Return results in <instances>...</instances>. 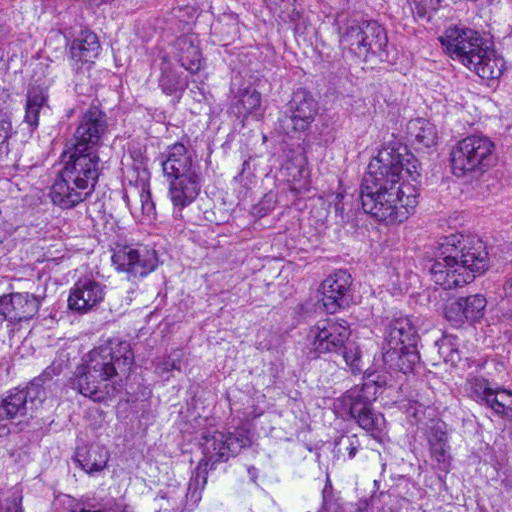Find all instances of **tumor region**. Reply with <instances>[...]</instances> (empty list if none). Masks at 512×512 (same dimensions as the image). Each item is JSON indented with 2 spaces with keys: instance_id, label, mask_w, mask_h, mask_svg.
I'll use <instances>...</instances> for the list:
<instances>
[{
  "instance_id": "e687c5a6",
  "label": "tumor region",
  "mask_w": 512,
  "mask_h": 512,
  "mask_svg": "<svg viewBox=\"0 0 512 512\" xmlns=\"http://www.w3.org/2000/svg\"><path fill=\"white\" fill-rule=\"evenodd\" d=\"M0 512H512V1H0Z\"/></svg>"
}]
</instances>
